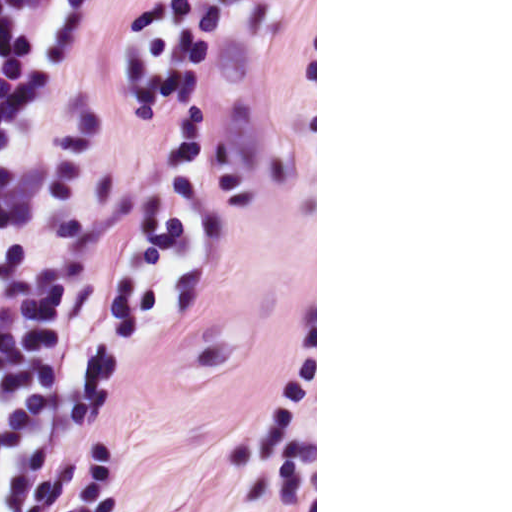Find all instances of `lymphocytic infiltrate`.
Here are the masks:
<instances>
[{"label":"lymphocytic infiltrate","mask_w":512,"mask_h":512,"mask_svg":"<svg viewBox=\"0 0 512 512\" xmlns=\"http://www.w3.org/2000/svg\"><path fill=\"white\" fill-rule=\"evenodd\" d=\"M94 1L0 0V512H41L99 419Z\"/></svg>","instance_id":"f902f5d3"}]
</instances>
